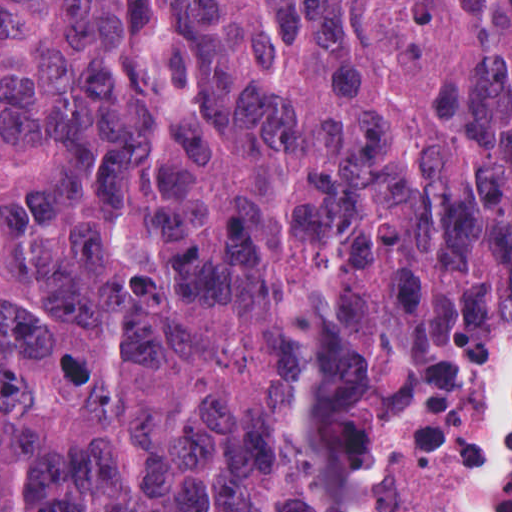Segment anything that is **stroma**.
Returning a JSON list of instances; mask_svg holds the SVG:
<instances>
[{
  "label": "stroma",
  "mask_w": 512,
  "mask_h": 512,
  "mask_svg": "<svg viewBox=\"0 0 512 512\" xmlns=\"http://www.w3.org/2000/svg\"><path fill=\"white\" fill-rule=\"evenodd\" d=\"M511 228L512 0H509L487 158L475 202V260L459 363L463 377L482 363Z\"/></svg>",
  "instance_id": "stroma-1"
}]
</instances>
